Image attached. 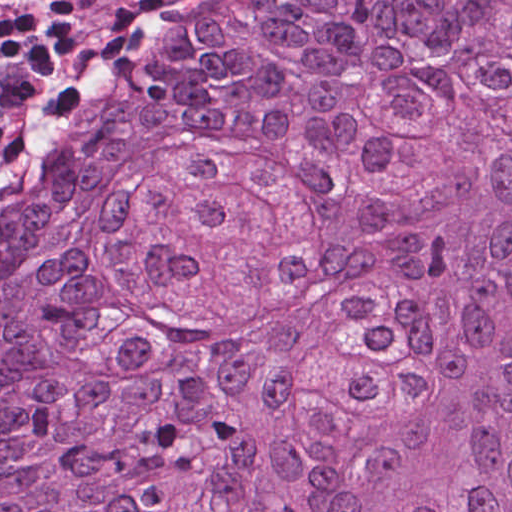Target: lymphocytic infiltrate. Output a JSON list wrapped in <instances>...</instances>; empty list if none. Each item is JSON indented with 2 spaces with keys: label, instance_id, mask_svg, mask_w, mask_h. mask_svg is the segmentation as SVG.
I'll return each mask as SVG.
<instances>
[{
  "label": "lymphocytic infiltrate",
  "instance_id": "obj_1",
  "mask_svg": "<svg viewBox=\"0 0 512 512\" xmlns=\"http://www.w3.org/2000/svg\"><path fill=\"white\" fill-rule=\"evenodd\" d=\"M155 0H0V238L124 105L164 47L144 33L110 68L95 49Z\"/></svg>",
  "mask_w": 512,
  "mask_h": 512
}]
</instances>
